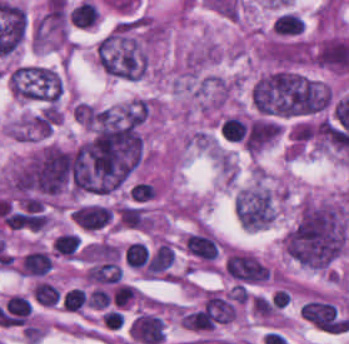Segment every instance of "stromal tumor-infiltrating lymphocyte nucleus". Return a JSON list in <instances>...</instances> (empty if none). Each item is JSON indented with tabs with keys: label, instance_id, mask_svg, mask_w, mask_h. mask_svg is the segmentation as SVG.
<instances>
[{
	"label": "stromal tumor-infiltrating lymphocyte nucleus",
	"instance_id": "5",
	"mask_svg": "<svg viewBox=\"0 0 349 344\" xmlns=\"http://www.w3.org/2000/svg\"><path fill=\"white\" fill-rule=\"evenodd\" d=\"M247 128L248 125L244 121L228 117L221 123L220 132L228 140H242Z\"/></svg>",
	"mask_w": 349,
	"mask_h": 344
},
{
	"label": "stromal tumor-infiltrating lymphocyte nucleus",
	"instance_id": "1",
	"mask_svg": "<svg viewBox=\"0 0 349 344\" xmlns=\"http://www.w3.org/2000/svg\"><path fill=\"white\" fill-rule=\"evenodd\" d=\"M111 217L112 210L102 203H82L72 212V221L75 225L88 232H97L103 229Z\"/></svg>",
	"mask_w": 349,
	"mask_h": 344
},
{
	"label": "stromal tumor-infiltrating lymphocyte nucleus",
	"instance_id": "6",
	"mask_svg": "<svg viewBox=\"0 0 349 344\" xmlns=\"http://www.w3.org/2000/svg\"><path fill=\"white\" fill-rule=\"evenodd\" d=\"M148 256V248L142 243L131 242L128 243L124 251V262L129 266L141 267L143 266Z\"/></svg>",
	"mask_w": 349,
	"mask_h": 344
},
{
	"label": "stromal tumor-infiltrating lymphocyte nucleus",
	"instance_id": "7",
	"mask_svg": "<svg viewBox=\"0 0 349 344\" xmlns=\"http://www.w3.org/2000/svg\"><path fill=\"white\" fill-rule=\"evenodd\" d=\"M87 302V295L80 287H73L66 291L62 306L67 311H80Z\"/></svg>",
	"mask_w": 349,
	"mask_h": 344
},
{
	"label": "stromal tumor-infiltrating lymphocyte nucleus",
	"instance_id": "3",
	"mask_svg": "<svg viewBox=\"0 0 349 344\" xmlns=\"http://www.w3.org/2000/svg\"><path fill=\"white\" fill-rule=\"evenodd\" d=\"M69 19L73 25L89 28L97 23L98 11L89 0H82L69 10Z\"/></svg>",
	"mask_w": 349,
	"mask_h": 344
},
{
	"label": "stromal tumor-infiltrating lymphocyte nucleus",
	"instance_id": "4",
	"mask_svg": "<svg viewBox=\"0 0 349 344\" xmlns=\"http://www.w3.org/2000/svg\"><path fill=\"white\" fill-rule=\"evenodd\" d=\"M32 294L40 305L55 306L60 299L58 290L45 281H38Z\"/></svg>",
	"mask_w": 349,
	"mask_h": 344
},
{
	"label": "stromal tumor-infiltrating lymphocyte nucleus",
	"instance_id": "2",
	"mask_svg": "<svg viewBox=\"0 0 349 344\" xmlns=\"http://www.w3.org/2000/svg\"><path fill=\"white\" fill-rule=\"evenodd\" d=\"M49 269V256L44 251L33 250L24 254L21 261L19 273H22L25 276L43 277L48 274Z\"/></svg>",
	"mask_w": 349,
	"mask_h": 344
}]
</instances>
